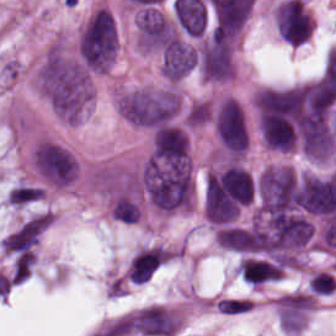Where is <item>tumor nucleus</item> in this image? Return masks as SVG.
Wrapping results in <instances>:
<instances>
[{
	"mask_svg": "<svg viewBox=\"0 0 336 336\" xmlns=\"http://www.w3.org/2000/svg\"><path fill=\"white\" fill-rule=\"evenodd\" d=\"M33 82L52 113L69 124H76L93 100L89 72L62 41L46 48L36 64Z\"/></svg>",
	"mask_w": 336,
	"mask_h": 336,
	"instance_id": "1",
	"label": "tumor nucleus"
},
{
	"mask_svg": "<svg viewBox=\"0 0 336 336\" xmlns=\"http://www.w3.org/2000/svg\"><path fill=\"white\" fill-rule=\"evenodd\" d=\"M114 106L131 125L148 129L183 130L190 116L171 86L126 88L116 93Z\"/></svg>",
	"mask_w": 336,
	"mask_h": 336,
	"instance_id": "2",
	"label": "tumor nucleus"
},
{
	"mask_svg": "<svg viewBox=\"0 0 336 336\" xmlns=\"http://www.w3.org/2000/svg\"><path fill=\"white\" fill-rule=\"evenodd\" d=\"M115 18L96 7L83 21L75 40V57L90 72H107L116 53Z\"/></svg>",
	"mask_w": 336,
	"mask_h": 336,
	"instance_id": "3",
	"label": "tumor nucleus"
},
{
	"mask_svg": "<svg viewBox=\"0 0 336 336\" xmlns=\"http://www.w3.org/2000/svg\"><path fill=\"white\" fill-rule=\"evenodd\" d=\"M30 168L37 184L45 189H65L78 173L75 157L47 136H40L32 144Z\"/></svg>",
	"mask_w": 336,
	"mask_h": 336,
	"instance_id": "4",
	"label": "tumor nucleus"
},
{
	"mask_svg": "<svg viewBox=\"0 0 336 336\" xmlns=\"http://www.w3.org/2000/svg\"><path fill=\"white\" fill-rule=\"evenodd\" d=\"M211 121L216 138L230 155L245 152L250 135V125L244 104L229 96H222L212 104Z\"/></svg>",
	"mask_w": 336,
	"mask_h": 336,
	"instance_id": "5",
	"label": "tumor nucleus"
},
{
	"mask_svg": "<svg viewBox=\"0 0 336 336\" xmlns=\"http://www.w3.org/2000/svg\"><path fill=\"white\" fill-rule=\"evenodd\" d=\"M122 336H172L179 331V310L149 304L124 314L120 318Z\"/></svg>",
	"mask_w": 336,
	"mask_h": 336,
	"instance_id": "6",
	"label": "tumor nucleus"
},
{
	"mask_svg": "<svg viewBox=\"0 0 336 336\" xmlns=\"http://www.w3.org/2000/svg\"><path fill=\"white\" fill-rule=\"evenodd\" d=\"M47 226L48 215L33 216L1 239V253L25 255L39 241Z\"/></svg>",
	"mask_w": 336,
	"mask_h": 336,
	"instance_id": "7",
	"label": "tumor nucleus"
},
{
	"mask_svg": "<svg viewBox=\"0 0 336 336\" xmlns=\"http://www.w3.org/2000/svg\"><path fill=\"white\" fill-rule=\"evenodd\" d=\"M108 213L114 221L128 225L139 221L142 209L136 194L122 192L111 197Z\"/></svg>",
	"mask_w": 336,
	"mask_h": 336,
	"instance_id": "8",
	"label": "tumor nucleus"
},
{
	"mask_svg": "<svg viewBox=\"0 0 336 336\" xmlns=\"http://www.w3.org/2000/svg\"><path fill=\"white\" fill-rule=\"evenodd\" d=\"M43 196L42 187L34 183L17 182L9 188L5 201L11 209H20L43 199Z\"/></svg>",
	"mask_w": 336,
	"mask_h": 336,
	"instance_id": "9",
	"label": "tumor nucleus"
}]
</instances>
